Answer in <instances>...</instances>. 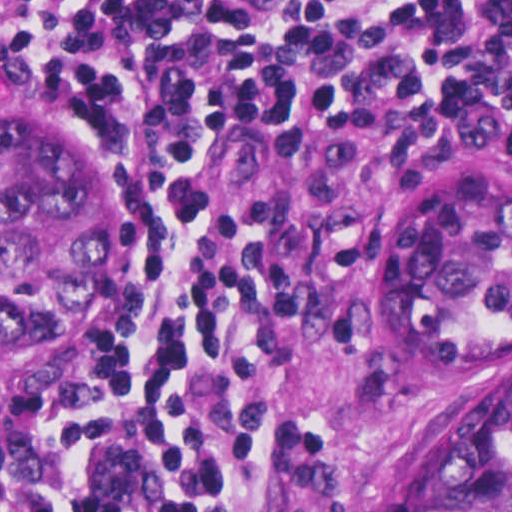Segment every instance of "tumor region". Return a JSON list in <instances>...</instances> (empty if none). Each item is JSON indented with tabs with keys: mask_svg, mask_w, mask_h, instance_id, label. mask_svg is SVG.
<instances>
[{
	"mask_svg": "<svg viewBox=\"0 0 512 512\" xmlns=\"http://www.w3.org/2000/svg\"><path fill=\"white\" fill-rule=\"evenodd\" d=\"M127 301V209L63 124L0 115V388L95 341ZM396 338L487 363L426 428L404 512H512V177L479 167L417 204L391 263Z\"/></svg>",
	"mask_w": 512,
	"mask_h": 512,
	"instance_id": "1",
	"label": "tumor region"
}]
</instances>
